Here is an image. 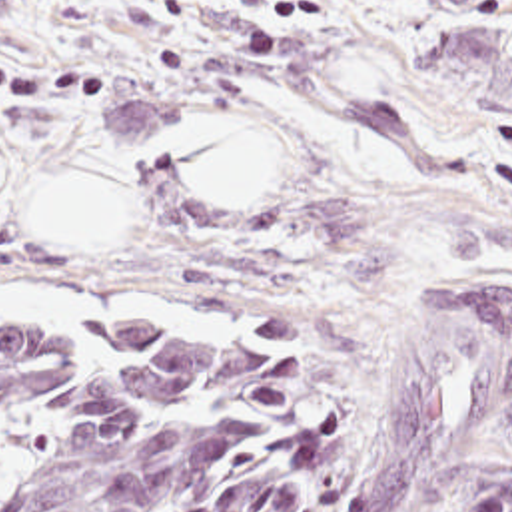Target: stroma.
<instances>
[{
    "label": "stroma",
    "mask_w": 512,
    "mask_h": 512,
    "mask_svg": "<svg viewBox=\"0 0 512 512\" xmlns=\"http://www.w3.org/2000/svg\"><path fill=\"white\" fill-rule=\"evenodd\" d=\"M0 55L109 73L103 109L0 107V281L201 309L0 323L261 325L333 379L325 512H351L434 263L480 253L512 281V0H0ZM223 117L275 151L259 205L203 209L171 171L173 131ZM89 169L129 199L119 247L31 239L43 191ZM488 472H512V412L416 512H466Z\"/></svg>",
    "instance_id": "obj_1"
}]
</instances>
